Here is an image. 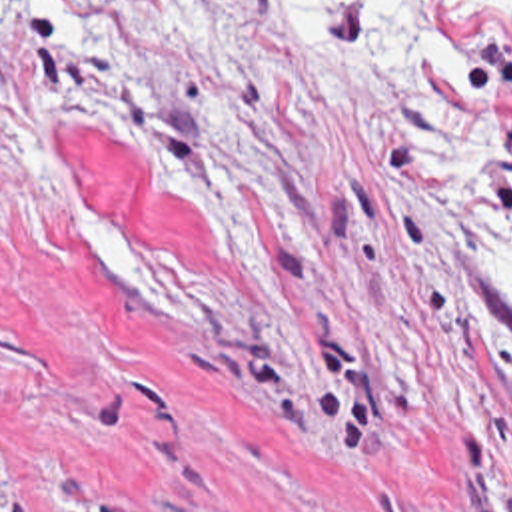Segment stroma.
<instances>
[{"label":"stroma","mask_w":512,"mask_h":512,"mask_svg":"<svg viewBox=\"0 0 512 512\" xmlns=\"http://www.w3.org/2000/svg\"><path fill=\"white\" fill-rule=\"evenodd\" d=\"M0 0V512H512V8Z\"/></svg>","instance_id":"stroma-1"}]
</instances>
